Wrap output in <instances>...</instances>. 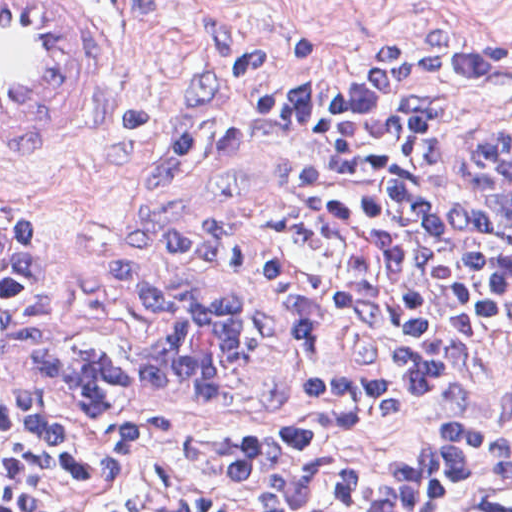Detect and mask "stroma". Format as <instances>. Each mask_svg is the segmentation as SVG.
<instances>
[{"label":"stroma","instance_id":"obj_1","mask_svg":"<svg viewBox=\"0 0 512 512\" xmlns=\"http://www.w3.org/2000/svg\"><path fill=\"white\" fill-rule=\"evenodd\" d=\"M69 1L102 54L78 107L0 158V227L84 255L114 311L204 279L258 314L265 361L237 402L131 397L170 429L286 443L373 404L387 387L389 310L340 214L347 121L270 106L267 89L284 70L437 43L512 55V0ZM469 126L432 131L428 196L464 250L512 270V210L456 183ZM430 428L422 399L384 429H335L324 444L343 461H392ZM509 478L465 480L435 512L480 506Z\"/></svg>","mask_w":512,"mask_h":512}]
</instances>
